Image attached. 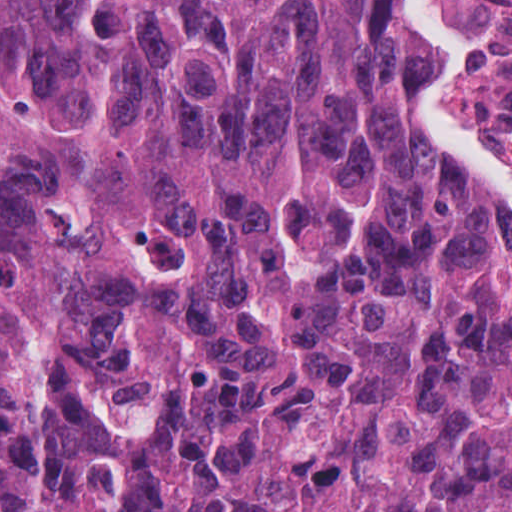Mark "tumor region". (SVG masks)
Segmentation results:
<instances>
[{
  "mask_svg": "<svg viewBox=\"0 0 512 512\" xmlns=\"http://www.w3.org/2000/svg\"><path fill=\"white\" fill-rule=\"evenodd\" d=\"M402 0H0V512H512V215L415 125Z\"/></svg>",
  "mask_w": 512,
  "mask_h": 512,
  "instance_id": "obj_1",
  "label": "tumor region"
}]
</instances>
